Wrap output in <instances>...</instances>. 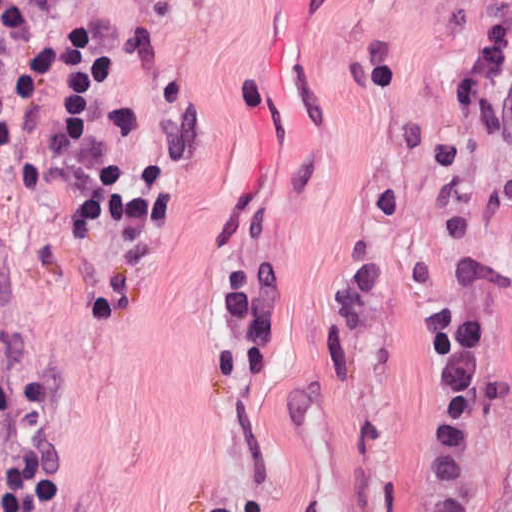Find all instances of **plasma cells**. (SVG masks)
<instances>
[{
	"label": "plasma cells",
	"instance_id": "1",
	"mask_svg": "<svg viewBox=\"0 0 512 512\" xmlns=\"http://www.w3.org/2000/svg\"><path fill=\"white\" fill-rule=\"evenodd\" d=\"M454 110L512 142V26L488 35L454 87ZM494 310L471 298H449L424 318L422 337L436 379L407 456L413 512H473L471 453L512 390L503 382L479 395L481 355Z\"/></svg>",
	"mask_w": 512,
	"mask_h": 512
}]
</instances>
